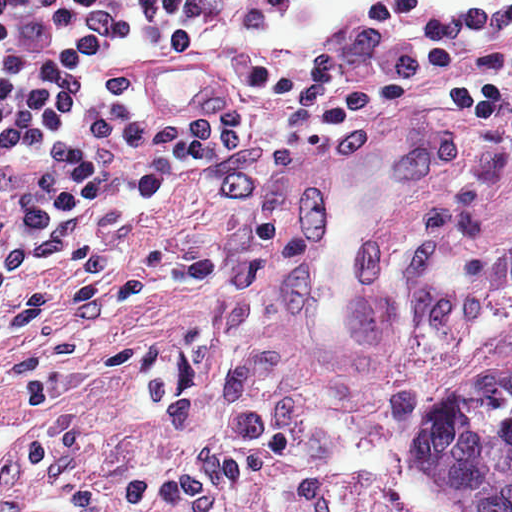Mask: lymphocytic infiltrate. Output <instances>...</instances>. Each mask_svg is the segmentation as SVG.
<instances>
[{
  "mask_svg": "<svg viewBox=\"0 0 512 512\" xmlns=\"http://www.w3.org/2000/svg\"><path fill=\"white\" fill-rule=\"evenodd\" d=\"M297 0H0V310L55 289L118 208L218 176L254 251L310 142L359 124L483 121L512 131V0H360L307 47L277 49ZM123 49L198 52L232 75L213 114H148Z\"/></svg>",
  "mask_w": 512,
  "mask_h": 512,
  "instance_id": "f902f5d3",
  "label": "lymphocytic infiltrate"
}]
</instances>
